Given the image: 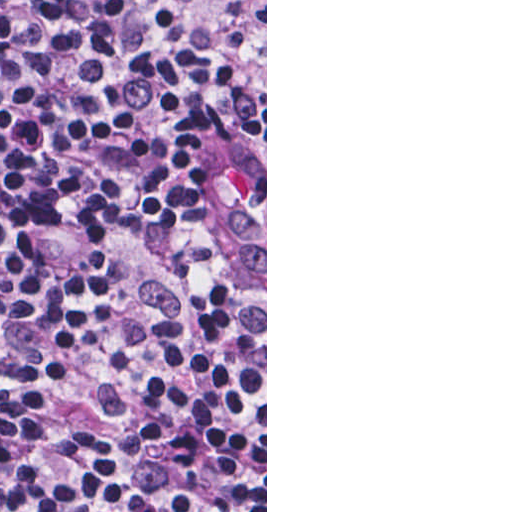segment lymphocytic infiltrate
Returning <instances> with one entry per match:
<instances>
[{
	"instance_id": "f902f5d3",
	"label": "lymphocytic infiltrate",
	"mask_w": 512,
	"mask_h": 512,
	"mask_svg": "<svg viewBox=\"0 0 512 512\" xmlns=\"http://www.w3.org/2000/svg\"><path fill=\"white\" fill-rule=\"evenodd\" d=\"M0 512H265V0H0Z\"/></svg>"
}]
</instances>
